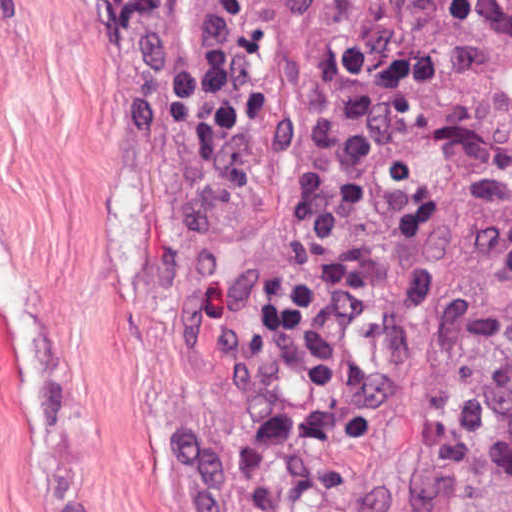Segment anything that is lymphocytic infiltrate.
I'll use <instances>...</instances> for the list:
<instances>
[{
    "mask_svg": "<svg viewBox=\"0 0 512 512\" xmlns=\"http://www.w3.org/2000/svg\"><path fill=\"white\" fill-rule=\"evenodd\" d=\"M319 0H118L168 95L232 145L259 141ZM498 0H415L397 50L351 72L259 293L265 410L229 490L242 512H312L366 382L345 307L352 256L444 140Z\"/></svg>",
    "mask_w": 512,
    "mask_h": 512,
    "instance_id": "f902f5d3",
    "label": "lymphocytic infiltrate"
}]
</instances>
